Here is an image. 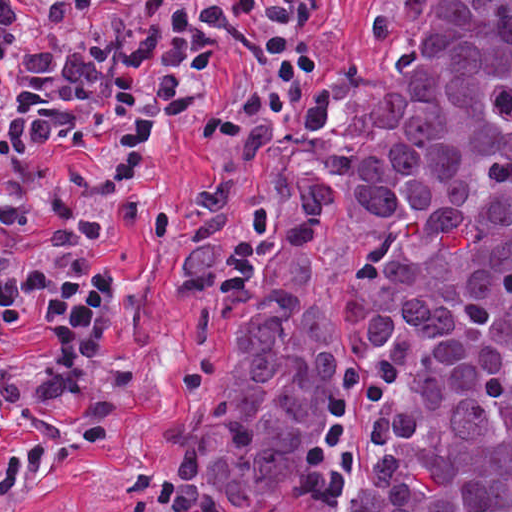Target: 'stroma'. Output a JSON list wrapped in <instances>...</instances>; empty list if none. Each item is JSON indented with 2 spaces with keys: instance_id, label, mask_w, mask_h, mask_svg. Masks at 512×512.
<instances>
[{
  "instance_id": "stroma-1",
  "label": "stroma",
  "mask_w": 512,
  "mask_h": 512,
  "mask_svg": "<svg viewBox=\"0 0 512 512\" xmlns=\"http://www.w3.org/2000/svg\"><path fill=\"white\" fill-rule=\"evenodd\" d=\"M392 0H313L320 66L272 114L230 162L193 157V136L210 120L228 82L210 78L198 117L162 144L154 163V209L146 228L126 237L119 254L123 295L107 334L143 357V378L123 389L119 429L70 455L21 512H130L150 494L171 512H189L171 478L168 440L184 413L224 321L220 294L186 291L176 276L174 246L210 207L245 201L279 151L308 94L358 69L374 52ZM25 240L0 232V256L23 267Z\"/></svg>"
}]
</instances>
